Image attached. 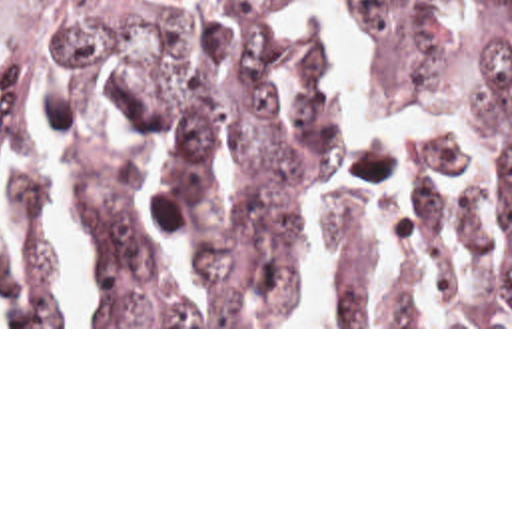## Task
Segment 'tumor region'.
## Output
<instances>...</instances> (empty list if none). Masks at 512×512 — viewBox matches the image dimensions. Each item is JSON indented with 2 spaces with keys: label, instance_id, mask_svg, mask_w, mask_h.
I'll list each match as a JSON object with an SVG mask.
<instances>
[{
  "label": "tumor region",
  "instance_id": "obj_1",
  "mask_svg": "<svg viewBox=\"0 0 512 512\" xmlns=\"http://www.w3.org/2000/svg\"><path fill=\"white\" fill-rule=\"evenodd\" d=\"M368 36L374 113L434 115L486 149L494 203L510 245L496 259L478 211L446 201L436 177L462 163L454 139L414 133L412 207L398 237L430 281L448 239L468 273L450 325H512V0H338ZM322 38L280 28L272 0H0V157L41 117L37 91L67 93L75 147L69 201L105 259V325H284L296 199L316 171L344 161L380 177L388 151L358 145L336 123L320 85ZM121 61L134 127L166 137L172 161L152 219L164 233L198 211L210 157L228 149L224 223L192 259L214 305H180L136 219V153L99 119V89ZM3 207L21 249L0 263V325H69L43 241L35 181L7 179ZM322 245L338 257L332 325H430L410 303L360 299L364 213L330 185Z\"/></svg>",
  "mask_w": 512,
  "mask_h": 512
}]
</instances>
